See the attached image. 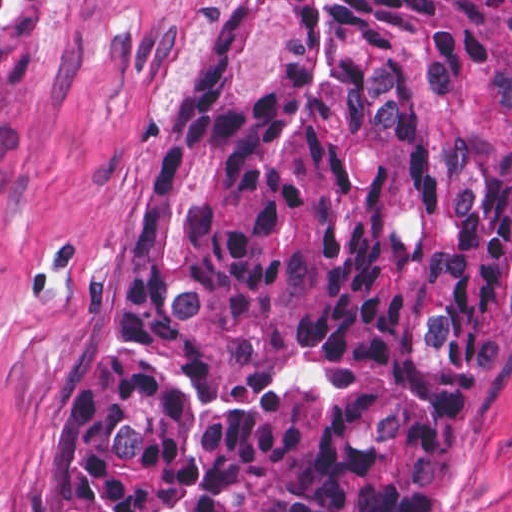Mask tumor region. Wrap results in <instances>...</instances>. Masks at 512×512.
I'll use <instances>...</instances> for the list:
<instances>
[{
  "instance_id": "tumor-region-1",
  "label": "tumor region",
  "mask_w": 512,
  "mask_h": 512,
  "mask_svg": "<svg viewBox=\"0 0 512 512\" xmlns=\"http://www.w3.org/2000/svg\"><path fill=\"white\" fill-rule=\"evenodd\" d=\"M50 11L0 1V109ZM512 335V1H254L186 100L74 512H426Z\"/></svg>"
}]
</instances>
